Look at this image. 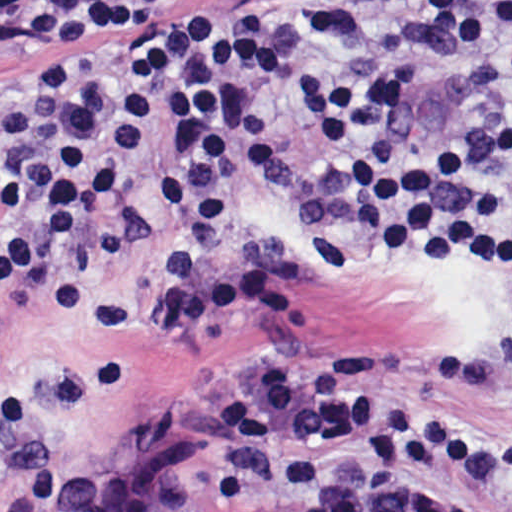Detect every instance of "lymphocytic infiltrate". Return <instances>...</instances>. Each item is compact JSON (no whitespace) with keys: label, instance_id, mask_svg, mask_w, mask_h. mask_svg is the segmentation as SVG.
I'll return each instance as SVG.
<instances>
[{"label":"lymphocytic infiltrate","instance_id":"1","mask_svg":"<svg viewBox=\"0 0 512 512\" xmlns=\"http://www.w3.org/2000/svg\"><path fill=\"white\" fill-rule=\"evenodd\" d=\"M182 1H26L11 38L29 76L0 109V302L25 293L63 322L86 318L82 250L130 198L134 174L173 145L158 206L172 228L148 286L162 340L226 320L277 324L294 310L283 272L239 261L236 166L263 201L294 209L322 273L344 280L391 253L438 267L512 272V130L419 150L395 116L424 86L416 67L352 69L278 38L237 48ZM325 116L295 129L239 60ZM512 393V330L479 353L384 344L313 362L242 367L207 403L221 446L216 492L237 512H478L425 474L512 487V438L405 397Z\"/></svg>","mask_w":512,"mask_h":512}]
</instances>
